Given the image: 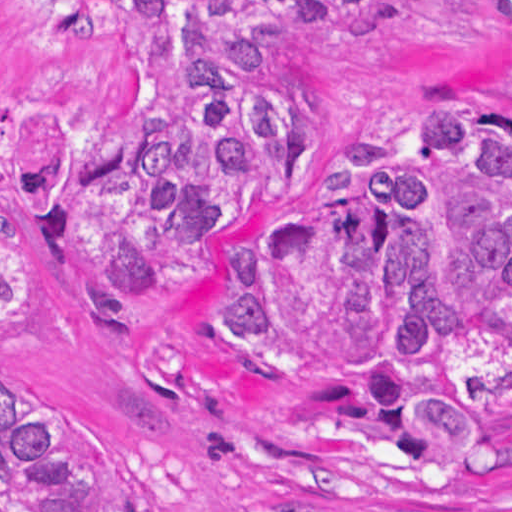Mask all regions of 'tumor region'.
I'll return each instance as SVG.
<instances>
[{
    "mask_svg": "<svg viewBox=\"0 0 512 512\" xmlns=\"http://www.w3.org/2000/svg\"><path fill=\"white\" fill-rule=\"evenodd\" d=\"M387 1L0 0V66L54 22L114 38V82L36 164L50 232L109 328L210 252L233 283L210 304L230 367L325 382L318 437H388L459 473L490 463L512 416L511 128L442 102L419 142L369 137L336 156L322 211L217 242L325 169L323 96L290 33ZM492 2L512 40V0ZM21 156L0 112V339L37 298L10 234ZM31 401H0V512H156L108 434Z\"/></svg>",
    "mask_w": 512,
    "mask_h": 512,
    "instance_id": "tumor-region-1",
    "label": "tumor region"
}]
</instances>
